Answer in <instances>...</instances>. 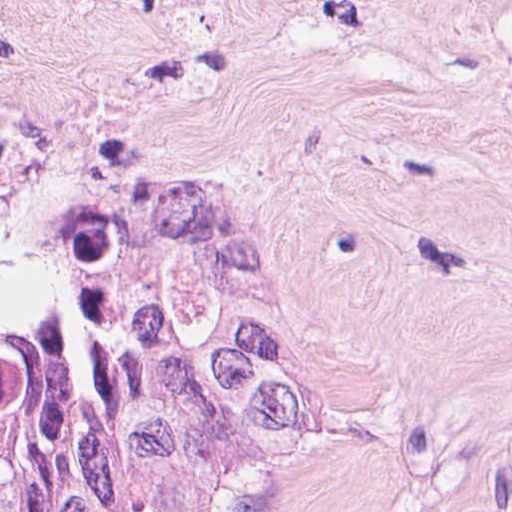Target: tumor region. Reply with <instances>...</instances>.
Returning <instances> with one entry per match:
<instances>
[{"mask_svg": "<svg viewBox=\"0 0 512 512\" xmlns=\"http://www.w3.org/2000/svg\"><path fill=\"white\" fill-rule=\"evenodd\" d=\"M0 512H282L261 348L230 317H0Z\"/></svg>", "mask_w": 512, "mask_h": 512, "instance_id": "e687c5a6", "label": "tumor region"}]
</instances>
